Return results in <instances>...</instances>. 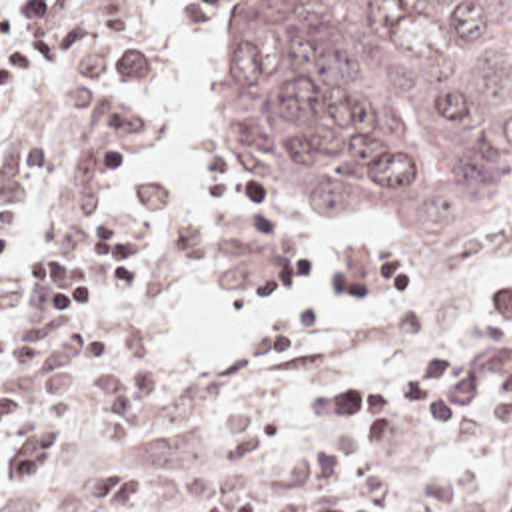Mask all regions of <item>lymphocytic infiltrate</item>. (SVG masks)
<instances>
[{
  "label": "lymphocytic infiltrate",
  "mask_w": 512,
  "mask_h": 512,
  "mask_svg": "<svg viewBox=\"0 0 512 512\" xmlns=\"http://www.w3.org/2000/svg\"><path fill=\"white\" fill-rule=\"evenodd\" d=\"M72 2H0V110L28 88L42 64L56 66V96L84 120L88 156L104 170L122 164L138 118L114 96L144 80V46L106 36L82 48L92 20ZM80 248H42L22 268H4L16 252V222L0 218V493L68 503L78 512H130L138 467L122 461L56 481H36L66 445L62 423L94 421L104 449L134 441L152 409V371L130 351L118 327L74 317L96 290L118 296L152 280L146 228L100 216L80 228ZM58 300H74L58 310Z\"/></svg>",
  "instance_id": "1"
}]
</instances>
